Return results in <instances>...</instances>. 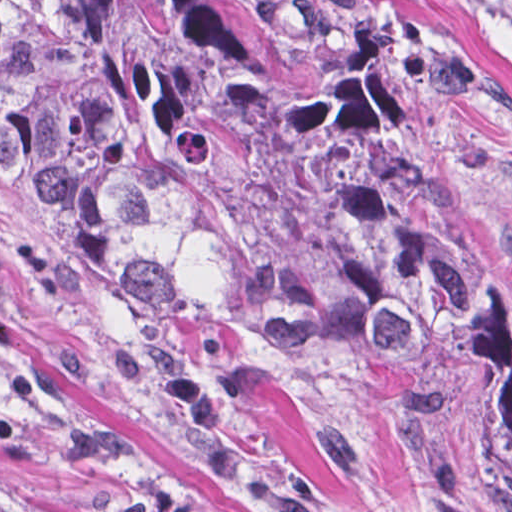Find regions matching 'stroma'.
Returning <instances> with one entry per match:
<instances>
[{
    "instance_id": "stroma-1",
    "label": "stroma",
    "mask_w": 512,
    "mask_h": 512,
    "mask_svg": "<svg viewBox=\"0 0 512 512\" xmlns=\"http://www.w3.org/2000/svg\"><path fill=\"white\" fill-rule=\"evenodd\" d=\"M240 1L338 42L512 263V0ZM0 512H512V488L432 390L148 350L0 174Z\"/></svg>"
}]
</instances>
